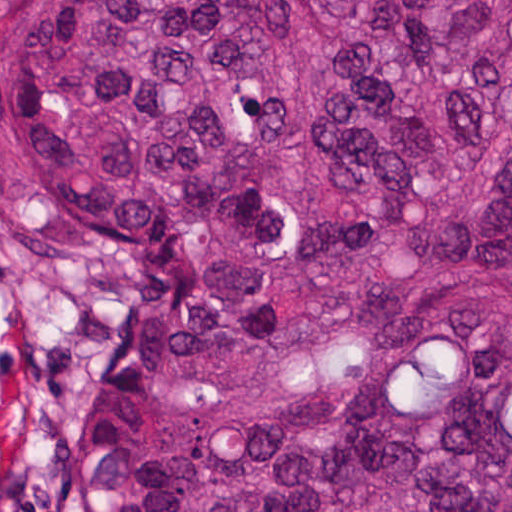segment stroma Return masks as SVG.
Segmentation results:
<instances>
[{
  "mask_svg": "<svg viewBox=\"0 0 512 512\" xmlns=\"http://www.w3.org/2000/svg\"><path fill=\"white\" fill-rule=\"evenodd\" d=\"M0 11V512H57L91 426L118 224L47 148Z\"/></svg>",
  "mask_w": 512,
  "mask_h": 512,
  "instance_id": "obj_1",
  "label": "stroma"
}]
</instances>
